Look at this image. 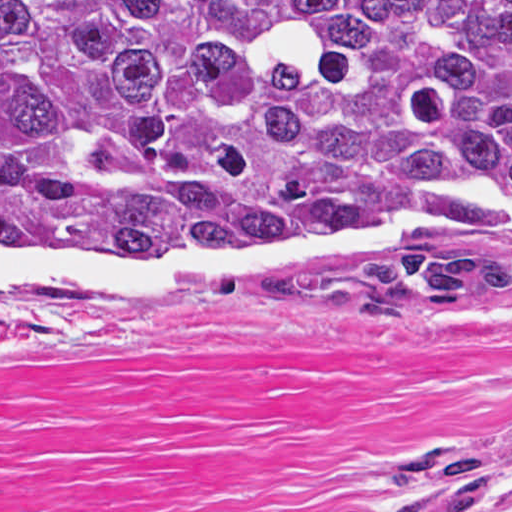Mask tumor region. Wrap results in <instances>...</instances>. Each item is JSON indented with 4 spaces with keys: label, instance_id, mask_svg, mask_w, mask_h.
<instances>
[{
    "label": "tumor region",
    "instance_id": "tumor-region-1",
    "mask_svg": "<svg viewBox=\"0 0 512 512\" xmlns=\"http://www.w3.org/2000/svg\"><path fill=\"white\" fill-rule=\"evenodd\" d=\"M512 203V0H0V211L64 244L300 240ZM512 303L503 233L320 278Z\"/></svg>",
    "mask_w": 512,
    "mask_h": 512
}]
</instances>
